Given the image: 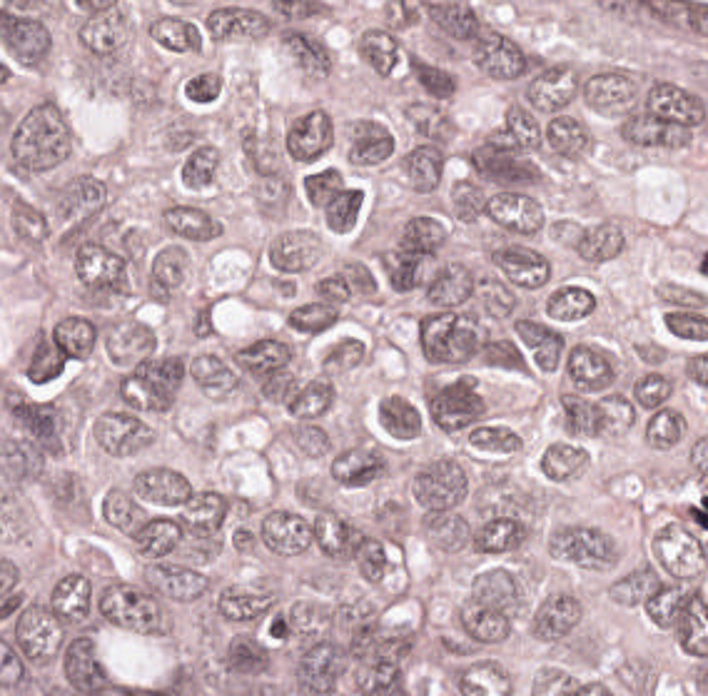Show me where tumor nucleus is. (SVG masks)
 <instances>
[{"instance_id": "tumor-nucleus-1", "label": "tumor nucleus", "mask_w": 708, "mask_h": 696, "mask_svg": "<svg viewBox=\"0 0 708 696\" xmlns=\"http://www.w3.org/2000/svg\"><path fill=\"white\" fill-rule=\"evenodd\" d=\"M416 331L418 352L433 370H472L499 360V330L484 311L431 304Z\"/></svg>"}, {"instance_id": "tumor-nucleus-2", "label": "tumor nucleus", "mask_w": 708, "mask_h": 696, "mask_svg": "<svg viewBox=\"0 0 708 696\" xmlns=\"http://www.w3.org/2000/svg\"><path fill=\"white\" fill-rule=\"evenodd\" d=\"M4 155L19 173H35L60 160L65 117L52 99H39L7 116L1 124Z\"/></svg>"}, {"instance_id": "tumor-nucleus-3", "label": "tumor nucleus", "mask_w": 708, "mask_h": 696, "mask_svg": "<svg viewBox=\"0 0 708 696\" xmlns=\"http://www.w3.org/2000/svg\"><path fill=\"white\" fill-rule=\"evenodd\" d=\"M416 411L431 427L453 435L477 433L487 420L482 389L464 371H438Z\"/></svg>"}, {"instance_id": "tumor-nucleus-4", "label": "tumor nucleus", "mask_w": 708, "mask_h": 696, "mask_svg": "<svg viewBox=\"0 0 708 696\" xmlns=\"http://www.w3.org/2000/svg\"><path fill=\"white\" fill-rule=\"evenodd\" d=\"M522 597L517 571L491 564L472 584L461 625L466 639H492L518 615Z\"/></svg>"}, {"instance_id": "tumor-nucleus-5", "label": "tumor nucleus", "mask_w": 708, "mask_h": 696, "mask_svg": "<svg viewBox=\"0 0 708 696\" xmlns=\"http://www.w3.org/2000/svg\"><path fill=\"white\" fill-rule=\"evenodd\" d=\"M467 488L464 466L431 456L408 479L412 508L421 522H452Z\"/></svg>"}, {"instance_id": "tumor-nucleus-6", "label": "tumor nucleus", "mask_w": 708, "mask_h": 696, "mask_svg": "<svg viewBox=\"0 0 708 696\" xmlns=\"http://www.w3.org/2000/svg\"><path fill=\"white\" fill-rule=\"evenodd\" d=\"M589 521L553 526L576 567H579Z\"/></svg>"}]
</instances>
